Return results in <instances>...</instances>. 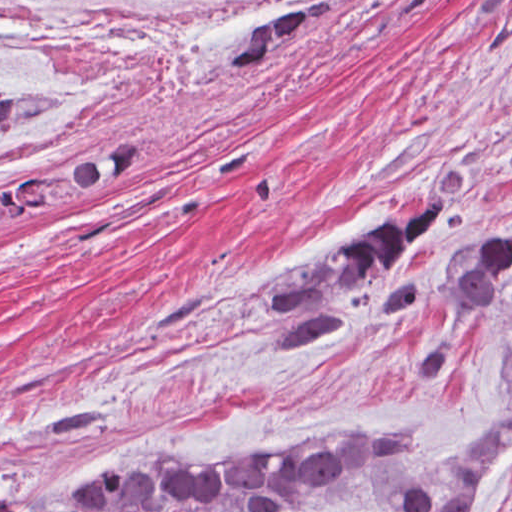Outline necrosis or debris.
<instances>
[{
	"mask_svg": "<svg viewBox=\"0 0 512 512\" xmlns=\"http://www.w3.org/2000/svg\"><path fill=\"white\" fill-rule=\"evenodd\" d=\"M303 0H0V91L102 94L236 42ZM60 150L0 138V211L47 182Z\"/></svg>",
	"mask_w": 512,
	"mask_h": 512,
	"instance_id": "obj_1",
	"label": "necrosis or debris"
}]
</instances>
